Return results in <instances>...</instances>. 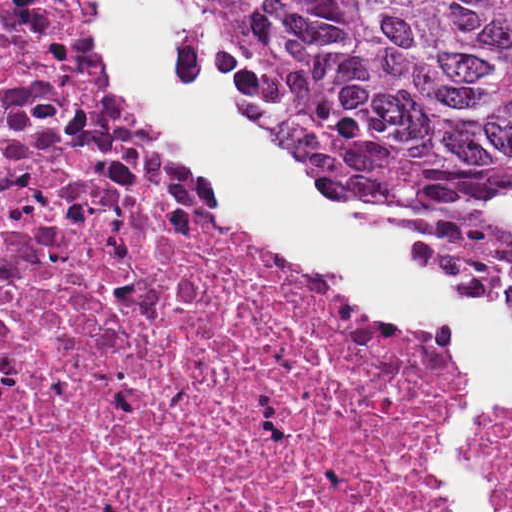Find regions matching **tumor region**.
<instances>
[{
  "mask_svg": "<svg viewBox=\"0 0 512 512\" xmlns=\"http://www.w3.org/2000/svg\"><path fill=\"white\" fill-rule=\"evenodd\" d=\"M215 90L348 198L419 217L474 299H512V0H196Z\"/></svg>",
  "mask_w": 512,
  "mask_h": 512,
  "instance_id": "obj_1",
  "label": "tumor region"
}]
</instances>
